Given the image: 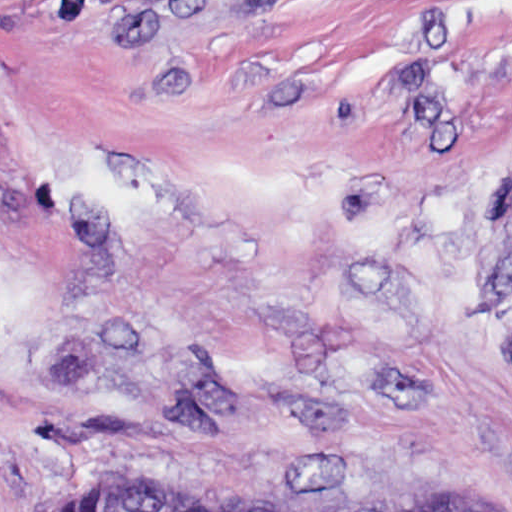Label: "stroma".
Here are the masks:
<instances>
[{
  "label": "stroma",
  "mask_w": 512,
  "mask_h": 512,
  "mask_svg": "<svg viewBox=\"0 0 512 512\" xmlns=\"http://www.w3.org/2000/svg\"><path fill=\"white\" fill-rule=\"evenodd\" d=\"M512 512V0H0V512Z\"/></svg>",
  "instance_id": "obj_1"
}]
</instances>
